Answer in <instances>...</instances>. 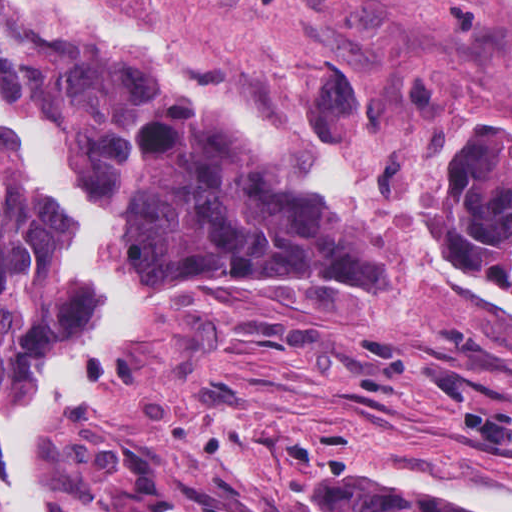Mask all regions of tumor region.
<instances>
[{
	"instance_id": "1",
	"label": "tumor region",
	"mask_w": 512,
	"mask_h": 512,
	"mask_svg": "<svg viewBox=\"0 0 512 512\" xmlns=\"http://www.w3.org/2000/svg\"><path fill=\"white\" fill-rule=\"evenodd\" d=\"M0 94L75 149L89 196L124 224L110 267L142 296L126 355L168 310L215 284L384 286L342 223L124 43L0 18ZM438 179L459 245L512 283V116L467 128ZM71 228L19 130L0 119V410L94 302L92 280L62 259ZM367 484L366 468L327 477L310 512H476L438 510L422 492L375 477L365 501ZM96 498L109 512H236L186 499L141 455L97 454Z\"/></svg>"
}]
</instances>
